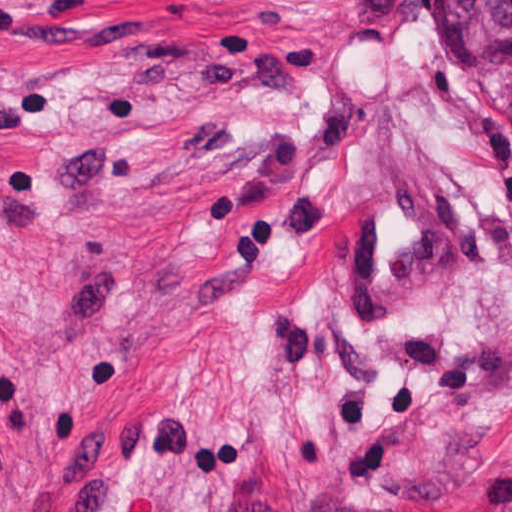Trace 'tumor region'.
<instances>
[{"label": "tumor region", "instance_id": "1", "mask_svg": "<svg viewBox=\"0 0 512 512\" xmlns=\"http://www.w3.org/2000/svg\"><path fill=\"white\" fill-rule=\"evenodd\" d=\"M448 16L478 40L512 46V0H439Z\"/></svg>", "mask_w": 512, "mask_h": 512}]
</instances>
